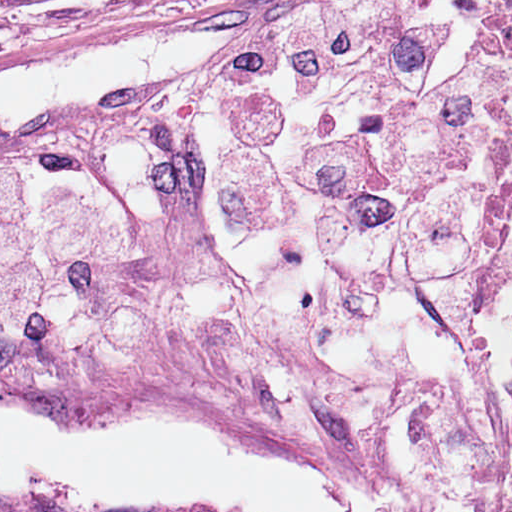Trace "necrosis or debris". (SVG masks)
Returning a JSON list of instances; mask_svg holds the SVG:
<instances>
[{"mask_svg":"<svg viewBox=\"0 0 512 512\" xmlns=\"http://www.w3.org/2000/svg\"><path fill=\"white\" fill-rule=\"evenodd\" d=\"M499 24L512 33V15L501 17ZM509 461L512 471V371L509 381Z\"/></svg>","mask_w":512,"mask_h":512,"instance_id":"necrosis-or-debris-1","label":"necrosis or debris"}]
</instances>
